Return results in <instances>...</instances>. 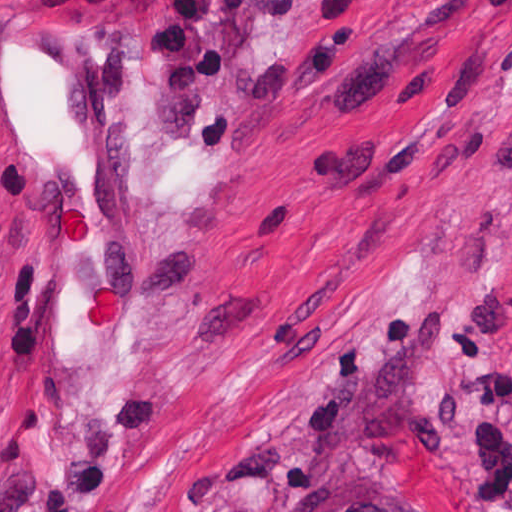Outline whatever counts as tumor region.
<instances>
[{"instance_id":"obj_1","label":"tumor region","mask_w":512,"mask_h":512,"mask_svg":"<svg viewBox=\"0 0 512 512\" xmlns=\"http://www.w3.org/2000/svg\"><path fill=\"white\" fill-rule=\"evenodd\" d=\"M319 512H410L386 479L349 476L337 482L322 500Z\"/></svg>"}]
</instances>
